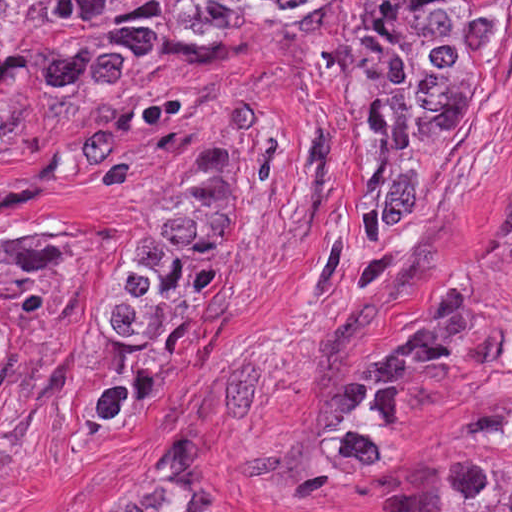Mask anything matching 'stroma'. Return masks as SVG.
<instances>
[{
	"instance_id": "obj_1",
	"label": "stroma",
	"mask_w": 512,
	"mask_h": 512,
	"mask_svg": "<svg viewBox=\"0 0 512 512\" xmlns=\"http://www.w3.org/2000/svg\"><path fill=\"white\" fill-rule=\"evenodd\" d=\"M184 165L225 232L179 289L153 407L106 428L108 284ZM0 324V512L156 508L208 433L240 512H445L457 460L512 464V17L487 106L394 231L354 45L126 78L80 153L0 168Z\"/></svg>"
}]
</instances>
